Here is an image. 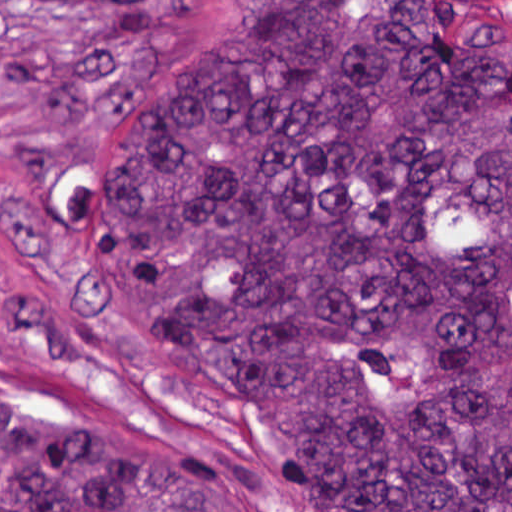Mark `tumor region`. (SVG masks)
Wrapping results in <instances>:
<instances>
[{
  "label": "tumor region",
  "mask_w": 512,
  "mask_h": 512,
  "mask_svg": "<svg viewBox=\"0 0 512 512\" xmlns=\"http://www.w3.org/2000/svg\"><path fill=\"white\" fill-rule=\"evenodd\" d=\"M119 115L67 228L303 512H512V39L236 1ZM0 512H255L217 461L0 410Z\"/></svg>",
  "instance_id": "e687c5a6"
}]
</instances>
